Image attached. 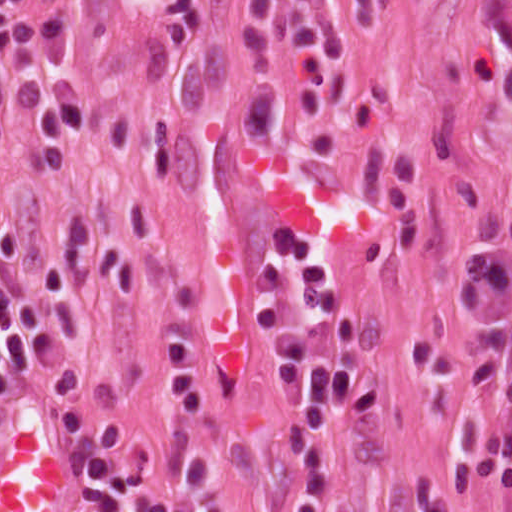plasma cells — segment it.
I'll return each mask as SVG.
<instances>
[{"label": "plasma cells", "mask_w": 512, "mask_h": 512, "mask_svg": "<svg viewBox=\"0 0 512 512\" xmlns=\"http://www.w3.org/2000/svg\"><path fill=\"white\" fill-rule=\"evenodd\" d=\"M287 73L304 114L321 110L320 97L302 76L310 54L342 57V36L329 8L284 5ZM22 248L17 225L0 232V400L32 384L61 352L88 338L80 305L54 254L35 257L26 288L16 292L10 273ZM508 318V276L478 266L464 277L455 320L462 326H495ZM252 323L279 385L282 411L297 417V455L303 472L295 512H323L335 481L337 427L342 412L369 414L381 381L360 363L311 347V332L324 328L339 341H355L360 320L345 302L327 253L283 221L258 269ZM503 351L501 335L446 353L419 343L410 349L415 371L440 388L428 402L451 426L455 481L477 498L512 512V339L498 365L479 450L483 410ZM168 365L182 404L188 481L173 497L151 493L152 451L126 419L107 420L62 410L61 424L78 459L79 512H234L221 458L205 441L203 426L214 397L203 356L189 343L175 344ZM417 512H468L448 505L432 476L420 470Z\"/></svg>", "instance_id": "1"}]
</instances>
